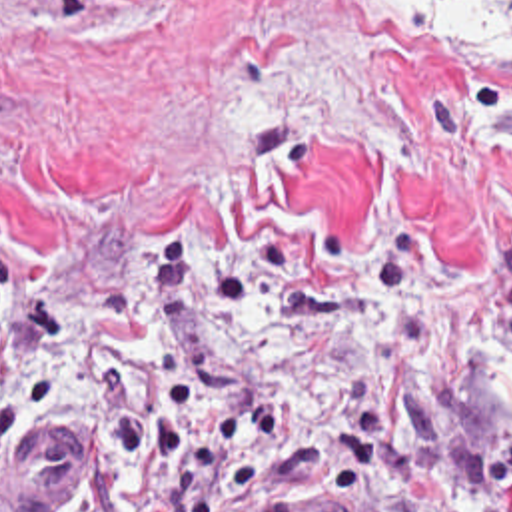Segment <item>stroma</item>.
I'll list each match as a JSON object with an SVG mask.
<instances>
[{"label": "stroma", "instance_id": "1", "mask_svg": "<svg viewBox=\"0 0 512 512\" xmlns=\"http://www.w3.org/2000/svg\"><path fill=\"white\" fill-rule=\"evenodd\" d=\"M381 0H0V252L78 316L174 248L170 346L230 418L367 364L419 458L512 430V111ZM62 364L0 512H72ZM210 512H343L326 466Z\"/></svg>", "mask_w": 512, "mask_h": 512}]
</instances>
